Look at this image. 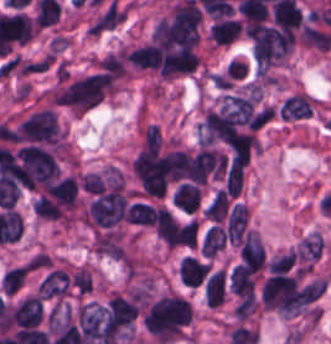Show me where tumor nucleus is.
<instances>
[{"label":"tumor nucleus","instance_id":"3e47fb67","mask_svg":"<svg viewBox=\"0 0 331 344\" xmlns=\"http://www.w3.org/2000/svg\"><path fill=\"white\" fill-rule=\"evenodd\" d=\"M27 275L26 263L6 269L2 279L0 290L5 295H12L19 290L25 282Z\"/></svg>","mask_w":331,"mask_h":344},{"label":"tumor nucleus","instance_id":"8087334f","mask_svg":"<svg viewBox=\"0 0 331 344\" xmlns=\"http://www.w3.org/2000/svg\"><path fill=\"white\" fill-rule=\"evenodd\" d=\"M204 299L209 306L216 308L226 299V272L222 267L207 274Z\"/></svg>","mask_w":331,"mask_h":344},{"label":"tumor nucleus","instance_id":"2f306a5c","mask_svg":"<svg viewBox=\"0 0 331 344\" xmlns=\"http://www.w3.org/2000/svg\"><path fill=\"white\" fill-rule=\"evenodd\" d=\"M191 317L190 302L169 291L151 302L142 315V323L154 344H169L183 335Z\"/></svg>","mask_w":331,"mask_h":344},{"label":"tumor nucleus","instance_id":"8643909e","mask_svg":"<svg viewBox=\"0 0 331 344\" xmlns=\"http://www.w3.org/2000/svg\"><path fill=\"white\" fill-rule=\"evenodd\" d=\"M9 317L16 327L35 329L43 317L41 297L26 294L10 308Z\"/></svg>","mask_w":331,"mask_h":344},{"label":"tumor nucleus","instance_id":"2083b535","mask_svg":"<svg viewBox=\"0 0 331 344\" xmlns=\"http://www.w3.org/2000/svg\"><path fill=\"white\" fill-rule=\"evenodd\" d=\"M211 268L210 263L184 256L178 263V278L181 283L189 287H197Z\"/></svg>","mask_w":331,"mask_h":344},{"label":"tumor nucleus","instance_id":"3d1891a8","mask_svg":"<svg viewBox=\"0 0 331 344\" xmlns=\"http://www.w3.org/2000/svg\"><path fill=\"white\" fill-rule=\"evenodd\" d=\"M325 242L319 231H311L304 235L295 246L294 253L299 262L309 269L322 254Z\"/></svg>","mask_w":331,"mask_h":344},{"label":"tumor nucleus","instance_id":"5ab6c2c4","mask_svg":"<svg viewBox=\"0 0 331 344\" xmlns=\"http://www.w3.org/2000/svg\"><path fill=\"white\" fill-rule=\"evenodd\" d=\"M238 258L241 267L253 273L258 274L264 268V249L261 240L255 232L246 231L238 250Z\"/></svg>","mask_w":331,"mask_h":344},{"label":"tumor nucleus","instance_id":"2cbd58db","mask_svg":"<svg viewBox=\"0 0 331 344\" xmlns=\"http://www.w3.org/2000/svg\"><path fill=\"white\" fill-rule=\"evenodd\" d=\"M315 100L305 93L294 92L281 103L278 111L279 118L292 121L305 118L310 114Z\"/></svg>","mask_w":331,"mask_h":344},{"label":"tumor nucleus","instance_id":"feef74b5","mask_svg":"<svg viewBox=\"0 0 331 344\" xmlns=\"http://www.w3.org/2000/svg\"><path fill=\"white\" fill-rule=\"evenodd\" d=\"M125 220L134 225L151 227L155 220L154 206L143 201H135L129 204Z\"/></svg>","mask_w":331,"mask_h":344},{"label":"tumor nucleus","instance_id":"c2bd9aea","mask_svg":"<svg viewBox=\"0 0 331 344\" xmlns=\"http://www.w3.org/2000/svg\"><path fill=\"white\" fill-rule=\"evenodd\" d=\"M154 229L163 245L169 251L173 249L176 237L175 220L165 205H158L154 220Z\"/></svg>","mask_w":331,"mask_h":344},{"label":"tumor nucleus","instance_id":"268c6acd","mask_svg":"<svg viewBox=\"0 0 331 344\" xmlns=\"http://www.w3.org/2000/svg\"><path fill=\"white\" fill-rule=\"evenodd\" d=\"M80 187L87 194L98 195L105 187L103 176L94 171H87L81 174Z\"/></svg>","mask_w":331,"mask_h":344},{"label":"tumor nucleus","instance_id":"f7901128","mask_svg":"<svg viewBox=\"0 0 331 344\" xmlns=\"http://www.w3.org/2000/svg\"><path fill=\"white\" fill-rule=\"evenodd\" d=\"M197 221L192 217L176 225L174 242L178 246L194 248L196 244Z\"/></svg>","mask_w":331,"mask_h":344}]
</instances>
